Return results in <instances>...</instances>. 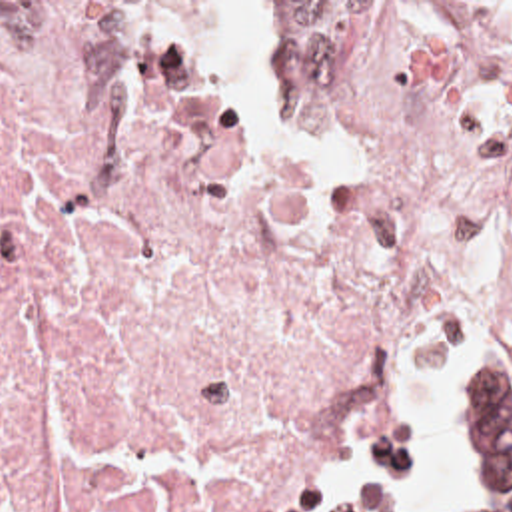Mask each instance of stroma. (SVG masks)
<instances>
[{
	"instance_id": "35a3bbf8",
	"label": "stroma",
	"mask_w": 512,
	"mask_h": 512,
	"mask_svg": "<svg viewBox=\"0 0 512 512\" xmlns=\"http://www.w3.org/2000/svg\"><path fill=\"white\" fill-rule=\"evenodd\" d=\"M0 2H512V0H0ZM457 335L423 345L435 375L447 431L449 512H471L459 475V383L495 345H512V319L481 313L463 297L423 303L403 331L389 385L361 423L333 417H291L297 457L315 512L357 511L333 501L329 477L343 459L365 475L399 471L409 455V365L419 337Z\"/></svg>"
}]
</instances>
